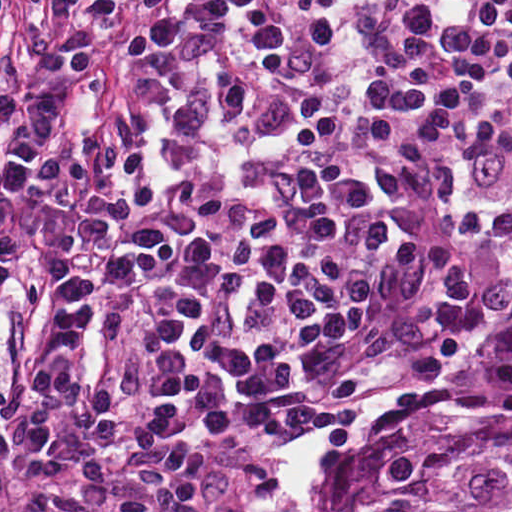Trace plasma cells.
Masks as SVG:
<instances>
[{"mask_svg":"<svg viewBox=\"0 0 512 512\" xmlns=\"http://www.w3.org/2000/svg\"><path fill=\"white\" fill-rule=\"evenodd\" d=\"M0 0V279L70 93L135 110L0 362V485L203 512L196 475L427 364L512 258V0Z\"/></svg>","mask_w":512,"mask_h":512,"instance_id":"9512152a","label":"plasma cells"}]
</instances>
